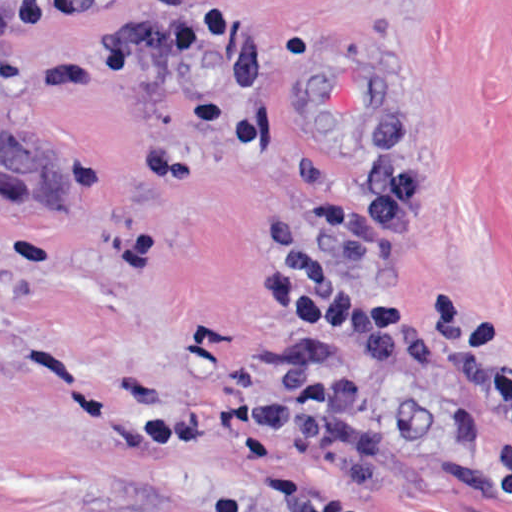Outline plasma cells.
I'll return each instance as SVG.
<instances>
[{"label":"plasma cells","mask_w":512,"mask_h":512,"mask_svg":"<svg viewBox=\"0 0 512 512\" xmlns=\"http://www.w3.org/2000/svg\"><path fill=\"white\" fill-rule=\"evenodd\" d=\"M288 512H335L331 496L294 484L288 499Z\"/></svg>","instance_id":"obj_1"}]
</instances>
